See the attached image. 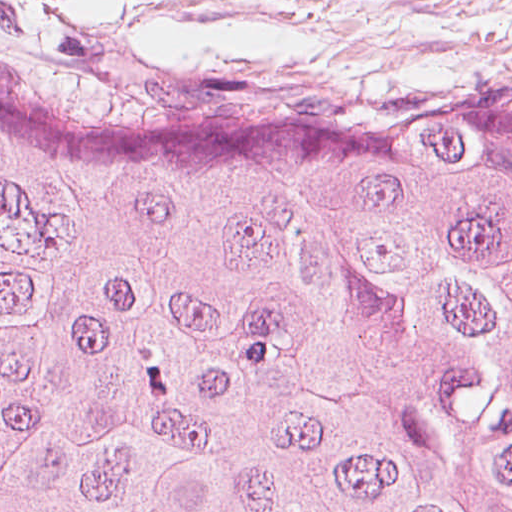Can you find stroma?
I'll return each instance as SVG.
<instances>
[{
	"mask_svg": "<svg viewBox=\"0 0 512 512\" xmlns=\"http://www.w3.org/2000/svg\"><path fill=\"white\" fill-rule=\"evenodd\" d=\"M0 74L348 122L512 110V0H0Z\"/></svg>",
	"mask_w": 512,
	"mask_h": 512,
	"instance_id": "1",
	"label": "stroma"
}]
</instances>
